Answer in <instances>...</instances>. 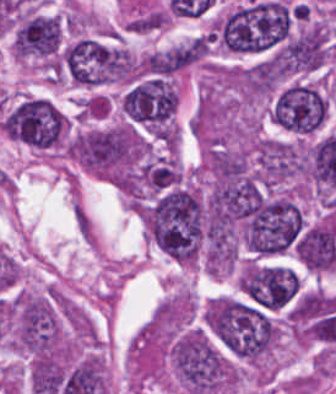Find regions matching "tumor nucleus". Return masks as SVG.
<instances>
[{
  "label": "tumor nucleus",
  "instance_id": "tumor-nucleus-1",
  "mask_svg": "<svg viewBox=\"0 0 336 394\" xmlns=\"http://www.w3.org/2000/svg\"><path fill=\"white\" fill-rule=\"evenodd\" d=\"M294 7L255 1L212 19V43L232 53H254L275 46L289 35Z\"/></svg>",
  "mask_w": 336,
  "mask_h": 394
},
{
  "label": "tumor nucleus",
  "instance_id": "tumor-nucleus-2",
  "mask_svg": "<svg viewBox=\"0 0 336 394\" xmlns=\"http://www.w3.org/2000/svg\"><path fill=\"white\" fill-rule=\"evenodd\" d=\"M169 352L185 394L219 392L235 387V364L205 330L189 327L172 338Z\"/></svg>",
  "mask_w": 336,
  "mask_h": 394
},
{
  "label": "tumor nucleus",
  "instance_id": "tumor-nucleus-3",
  "mask_svg": "<svg viewBox=\"0 0 336 394\" xmlns=\"http://www.w3.org/2000/svg\"><path fill=\"white\" fill-rule=\"evenodd\" d=\"M68 117L50 100L26 96L2 119L5 133L35 149H50L63 144Z\"/></svg>",
  "mask_w": 336,
  "mask_h": 394
},
{
  "label": "tumor nucleus",
  "instance_id": "tumor-nucleus-4",
  "mask_svg": "<svg viewBox=\"0 0 336 394\" xmlns=\"http://www.w3.org/2000/svg\"><path fill=\"white\" fill-rule=\"evenodd\" d=\"M64 74L74 83L106 84L123 77V54L119 46L81 37L64 45L58 53Z\"/></svg>",
  "mask_w": 336,
  "mask_h": 394
},
{
  "label": "tumor nucleus",
  "instance_id": "tumor-nucleus-5",
  "mask_svg": "<svg viewBox=\"0 0 336 394\" xmlns=\"http://www.w3.org/2000/svg\"><path fill=\"white\" fill-rule=\"evenodd\" d=\"M327 109V98L318 87L291 83L275 95L270 114L282 129L308 134L320 128Z\"/></svg>",
  "mask_w": 336,
  "mask_h": 394
},
{
  "label": "tumor nucleus",
  "instance_id": "tumor-nucleus-6",
  "mask_svg": "<svg viewBox=\"0 0 336 394\" xmlns=\"http://www.w3.org/2000/svg\"><path fill=\"white\" fill-rule=\"evenodd\" d=\"M63 23L58 15L33 13L16 21L14 53L18 58L53 65L61 46Z\"/></svg>",
  "mask_w": 336,
  "mask_h": 394
},
{
  "label": "tumor nucleus",
  "instance_id": "tumor-nucleus-7",
  "mask_svg": "<svg viewBox=\"0 0 336 394\" xmlns=\"http://www.w3.org/2000/svg\"><path fill=\"white\" fill-rule=\"evenodd\" d=\"M255 178L271 186L306 172L300 145L271 138H258L253 149Z\"/></svg>",
  "mask_w": 336,
  "mask_h": 394
}]
</instances>
